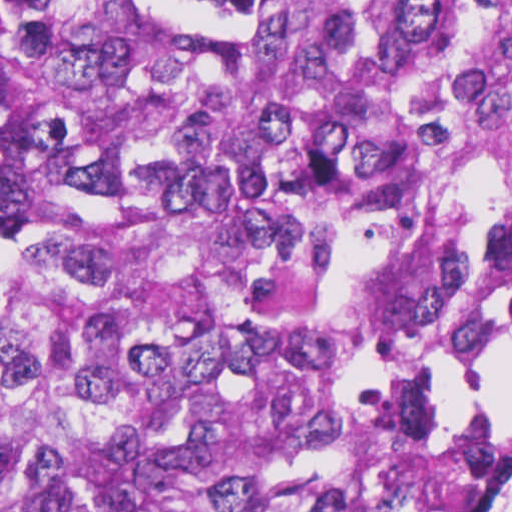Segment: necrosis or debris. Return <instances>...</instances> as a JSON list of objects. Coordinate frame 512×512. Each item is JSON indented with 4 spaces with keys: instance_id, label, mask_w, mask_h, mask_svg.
I'll use <instances>...</instances> for the list:
<instances>
[{
    "instance_id": "obj_1",
    "label": "necrosis or debris",
    "mask_w": 512,
    "mask_h": 512,
    "mask_svg": "<svg viewBox=\"0 0 512 512\" xmlns=\"http://www.w3.org/2000/svg\"><path fill=\"white\" fill-rule=\"evenodd\" d=\"M449 460L459 481L502 483L497 512H512V402L475 422Z\"/></svg>"
}]
</instances>
